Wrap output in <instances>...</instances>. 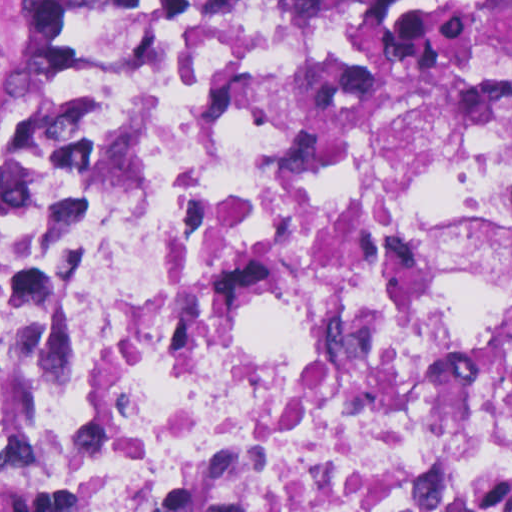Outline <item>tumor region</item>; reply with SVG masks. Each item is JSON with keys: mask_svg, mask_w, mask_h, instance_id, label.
<instances>
[{"mask_svg": "<svg viewBox=\"0 0 512 512\" xmlns=\"http://www.w3.org/2000/svg\"><path fill=\"white\" fill-rule=\"evenodd\" d=\"M100 0H47L0 35V164L53 90L76 47L82 23ZM512 26V0H427ZM274 489L266 451H217L157 512H264Z\"/></svg>", "mask_w": 512, "mask_h": 512, "instance_id": "obj_1", "label": "tumor region"}]
</instances>
